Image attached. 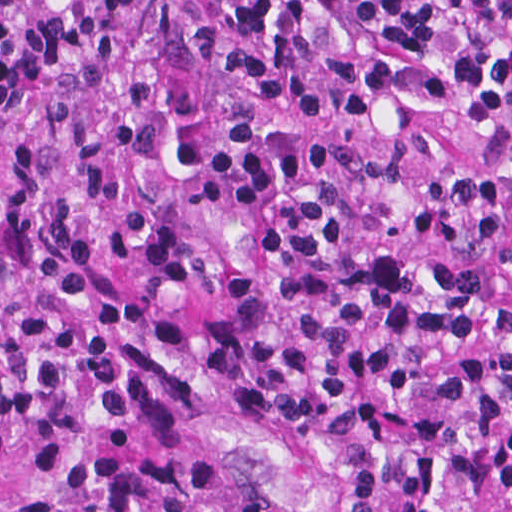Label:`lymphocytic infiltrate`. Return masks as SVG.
<instances>
[{
    "instance_id": "obj_1",
    "label": "lymphocytic infiltrate",
    "mask_w": 512,
    "mask_h": 512,
    "mask_svg": "<svg viewBox=\"0 0 512 512\" xmlns=\"http://www.w3.org/2000/svg\"><path fill=\"white\" fill-rule=\"evenodd\" d=\"M150 21L0 0V105ZM213 55L220 88L10 149L0 449L231 406L354 512H512V0H223Z\"/></svg>"
}]
</instances>
